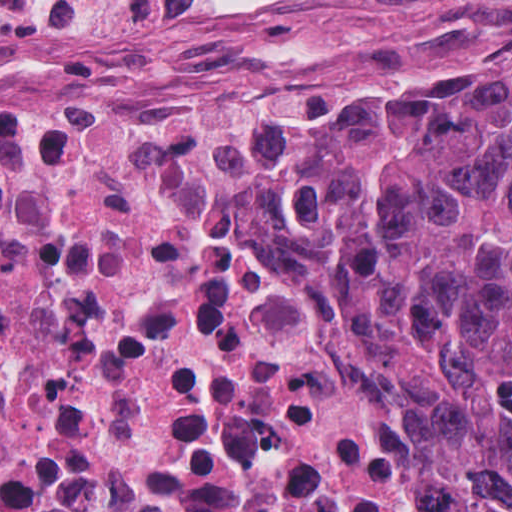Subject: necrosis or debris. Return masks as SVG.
Returning <instances> with one entry per match:
<instances>
[{
  "label": "necrosis or debris",
  "instance_id": "4bbe7bcc",
  "mask_svg": "<svg viewBox=\"0 0 512 512\" xmlns=\"http://www.w3.org/2000/svg\"><path fill=\"white\" fill-rule=\"evenodd\" d=\"M226 0H0V69ZM0 512H457L290 149L235 109L0 112Z\"/></svg>",
  "mask_w": 512,
  "mask_h": 512
}]
</instances>
